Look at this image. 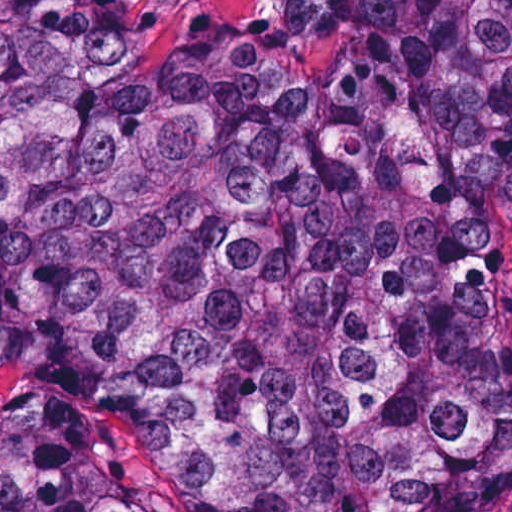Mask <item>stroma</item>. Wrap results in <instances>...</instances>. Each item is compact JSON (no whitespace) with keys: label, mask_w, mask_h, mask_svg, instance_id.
Returning a JSON list of instances; mask_svg holds the SVG:
<instances>
[{"label":"stroma","mask_w":512,"mask_h":512,"mask_svg":"<svg viewBox=\"0 0 512 512\" xmlns=\"http://www.w3.org/2000/svg\"><path fill=\"white\" fill-rule=\"evenodd\" d=\"M135 1L148 22H157V44H170L178 38L193 10H228L245 20L259 21L281 4V0ZM14 428L33 430L81 453L118 478L150 512H198L173 497L113 436L56 405L0 386V436ZM499 512H512V505Z\"/></svg>","instance_id":"obj_1"}]
</instances>
